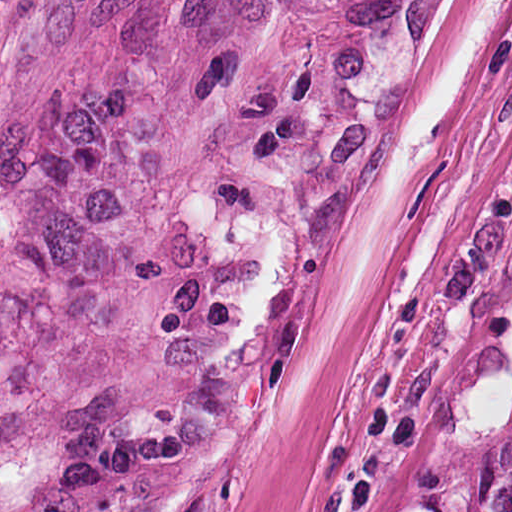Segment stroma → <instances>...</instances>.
Here are the masks:
<instances>
[{
    "mask_svg": "<svg viewBox=\"0 0 512 512\" xmlns=\"http://www.w3.org/2000/svg\"><path fill=\"white\" fill-rule=\"evenodd\" d=\"M81 0H0V250Z\"/></svg>",
    "mask_w": 512,
    "mask_h": 512,
    "instance_id": "35a3bbf8",
    "label": "stroma"
}]
</instances>
